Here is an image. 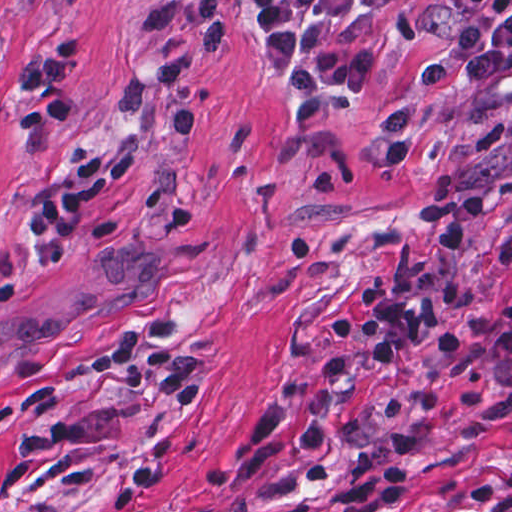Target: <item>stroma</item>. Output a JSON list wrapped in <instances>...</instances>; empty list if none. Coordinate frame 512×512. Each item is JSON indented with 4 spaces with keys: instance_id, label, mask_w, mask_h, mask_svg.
<instances>
[{
    "instance_id": "obj_1",
    "label": "stroma",
    "mask_w": 512,
    "mask_h": 512,
    "mask_svg": "<svg viewBox=\"0 0 512 512\" xmlns=\"http://www.w3.org/2000/svg\"><path fill=\"white\" fill-rule=\"evenodd\" d=\"M460 26L415 0L319 28L348 105L301 120L247 0H0V512H312L396 427L418 434L393 512H512V354L435 333L324 378L359 285L428 266L433 208L486 210L439 331L512 295V0L448 83L405 88L408 167L376 145ZM94 154L76 258L45 273L33 212Z\"/></svg>"
}]
</instances>
